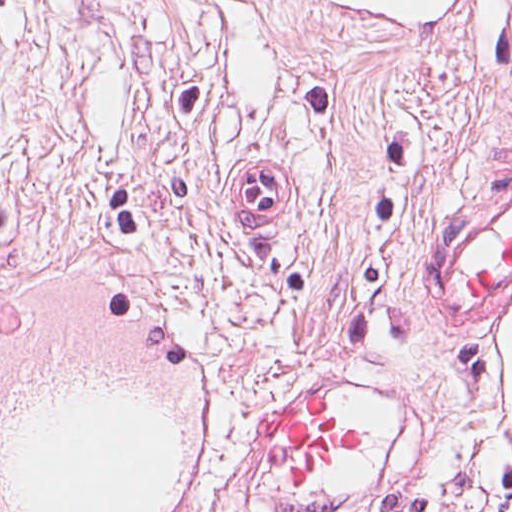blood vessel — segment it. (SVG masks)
Returning a JSON list of instances; mask_svg holds the SVG:
<instances>
[{
    "label": "blood vessel",
    "instance_id": "8fb6f2fc",
    "mask_svg": "<svg viewBox=\"0 0 512 512\" xmlns=\"http://www.w3.org/2000/svg\"><path fill=\"white\" fill-rule=\"evenodd\" d=\"M292 204L284 159H245L243 217ZM512 279V175L436 220L419 297L490 315ZM78 284L0 294V512H203L222 400L194 341L152 303Z\"/></svg>",
    "mask_w": 512,
    "mask_h": 512
}]
</instances>
